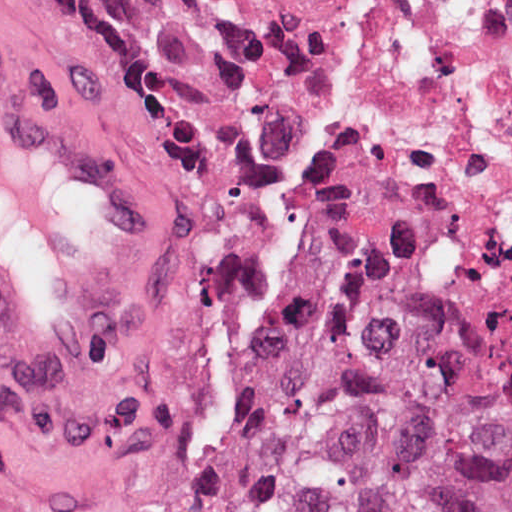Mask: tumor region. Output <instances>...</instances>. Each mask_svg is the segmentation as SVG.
Masks as SVG:
<instances>
[{"mask_svg": "<svg viewBox=\"0 0 512 512\" xmlns=\"http://www.w3.org/2000/svg\"><path fill=\"white\" fill-rule=\"evenodd\" d=\"M19 1L78 66L167 46L161 0ZM190 512H512V311L298 262L226 331Z\"/></svg>", "mask_w": 512, "mask_h": 512, "instance_id": "e687c5a6", "label": "tumor region"}]
</instances>
